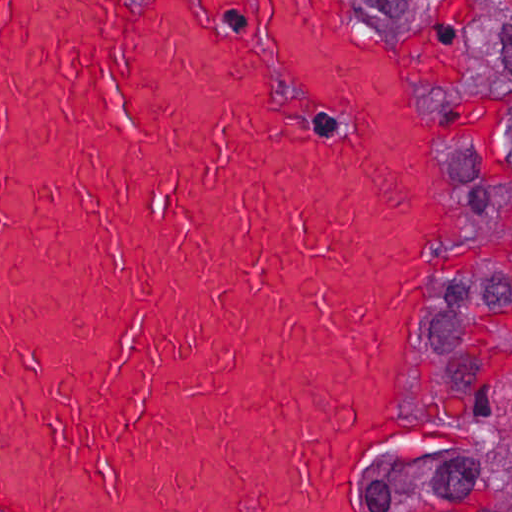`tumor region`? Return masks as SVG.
Listing matches in <instances>:
<instances>
[{"mask_svg":"<svg viewBox=\"0 0 512 512\" xmlns=\"http://www.w3.org/2000/svg\"><path fill=\"white\" fill-rule=\"evenodd\" d=\"M441 66L464 166L460 257L422 349L417 512H512V0H406Z\"/></svg>","mask_w":512,"mask_h":512,"instance_id":"tumor-region-1","label":"tumor region"}]
</instances>
